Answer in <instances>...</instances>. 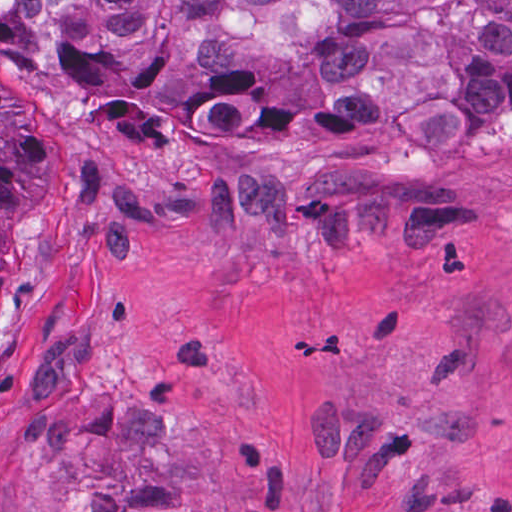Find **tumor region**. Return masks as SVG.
Listing matches in <instances>:
<instances>
[{"instance_id": "e687c5a6", "label": "tumor region", "mask_w": 512, "mask_h": 512, "mask_svg": "<svg viewBox=\"0 0 512 512\" xmlns=\"http://www.w3.org/2000/svg\"><path fill=\"white\" fill-rule=\"evenodd\" d=\"M0 52L231 168L362 146L444 164L512 109V0H0ZM10 119L0 68V232Z\"/></svg>"}]
</instances>
